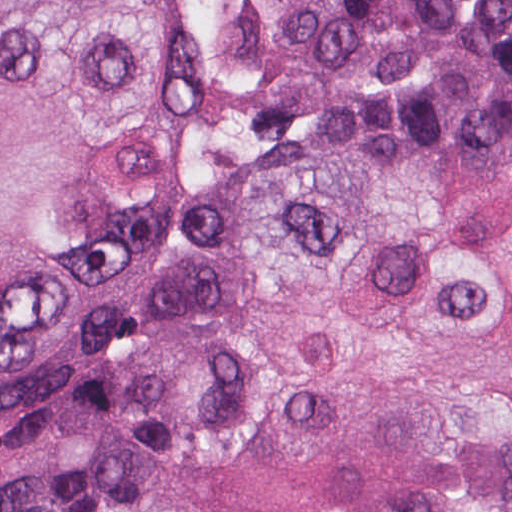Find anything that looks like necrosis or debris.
Returning a JSON list of instances; mask_svg holds the SVG:
<instances>
[{"label":"necrosis or debris","instance_id":"1","mask_svg":"<svg viewBox=\"0 0 512 512\" xmlns=\"http://www.w3.org/2000/svg\"><path fill=\"white\" fill-rule=\"evenodd\" d=\"M215 34V70L243 97L274 87L296 0H195Z\"/></svg>","mask_w":512,"mask_h":512}]
</instances>
